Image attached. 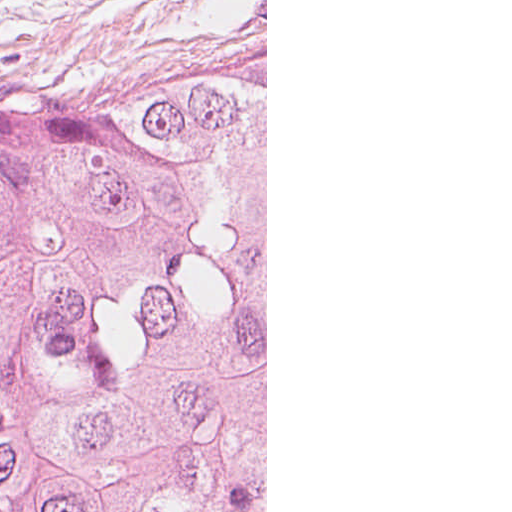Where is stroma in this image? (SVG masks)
Here are the masks:
<instances>
[{
	"label": "stroma",
	"mask_w": 512,
	"mask_h": 512,
	"mask_svg": "<svg viewBox=\"0 0 512 512\" xmlns=\"http://www.w3.org/2000/svg\"><path fill=\"white\" fill-rule=\"evenodd\" d=\"M266 17L227 0H0V110L248 65Z\"/></svg>",
	"instance_id": "obj_1"
}]
</instances>
